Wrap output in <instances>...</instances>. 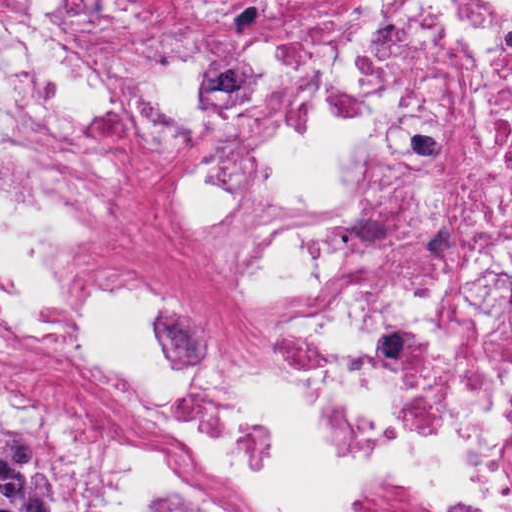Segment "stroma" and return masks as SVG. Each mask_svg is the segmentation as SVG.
Instances as JSON below:
<instances>
[{"mask_svg": "<svg viewBox=\"0 0 512 512\" xmlns=\"http://www.w3.org/2000/svg\"><path fill=\"white\" fill-rule=\"evenodd\" d=\"M7 428L34 444L40 469L55 492L69 505V512H87V487L80 472L54 447L38 414L16 399H0V429Z\"/></svg>", "mask_w": 512, "mask_h": 512, "instance_id": "stroma-1", "label": "stroma"}]
</instances>
